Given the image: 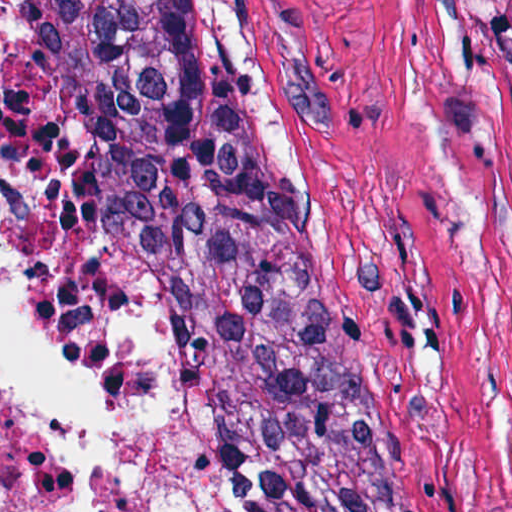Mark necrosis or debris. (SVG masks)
<instances>
[{"label": "necrosis or debris", "instance_id": "obj_1", "mask_svg": "<svg viewBox=\"0 0 512 512\" xmlns=\"http://www.w3.org/2000/svg\"><path fill=\"white\" fill-rule=\"evenodd\" d=\"M25 46L0 8V98ZM0 266L63 357L142 416L161 449L137 512H227L197 453L175 368L148 320H106L93 354L59 347L0 248ZM96 464L0 345V512H51L85 493Z\"/></svg>", "mask_w": 512, "mask_h": 512}]
</instances>
